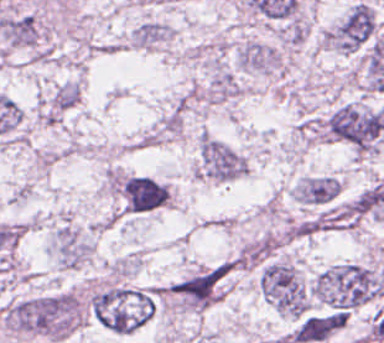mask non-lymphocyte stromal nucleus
Returning a JSON list of instances; mask_svg holds the SVG:
<instances>
[{"mask_svg": "<svg viewBox=\"0 0 384 343\" xmlns=\"http://www.w3.org/2000/svg\"><path fill=\"white\" fill-rule=\"evenodd\" d=\"M346 322L340 310L305 315L298 319L288 339L291 343H318Z\"/></svg>", "mask_w": 384, "mask_h": 343, "instance_id": "dd21d789", "label": "non-lymphocyte stromal nucleus"}]
</instances>
